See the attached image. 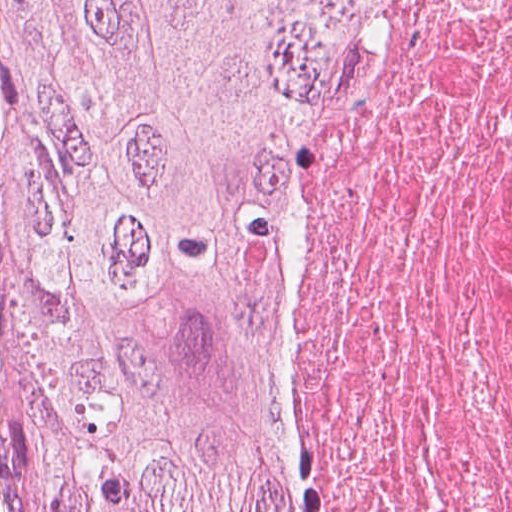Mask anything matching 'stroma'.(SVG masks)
I'll return each mask as SVG.
<instances>
[{
  "mask_svg": "<svg viewBox=\"0 0 512 512\" xmlns=\"http://www.w3.org/2000/svg\"><path fill=\"white\" fill-rule=\"evenodd\" d=\"M3 268L0 256V297ZM12 368L5 323L0 313V512H23L20 480V446L12 426L10 398Z\"/></svg>",
  "mask_w": 512,
  "mask_h": 512,
  "instance_id": "obj_1",
  "label": "stroma"
}]
</instances>
